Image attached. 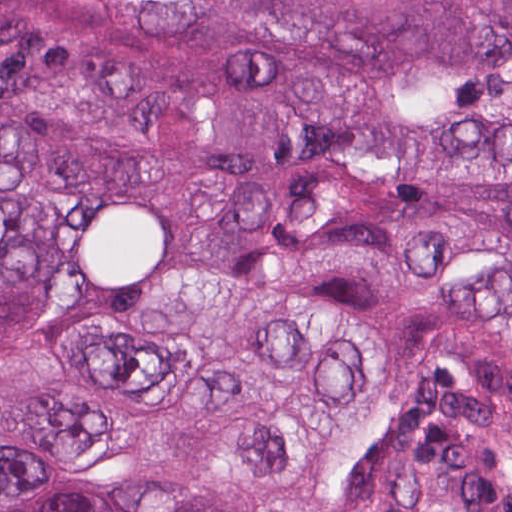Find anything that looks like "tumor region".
Segmentation results:
<instances>
[{
	"label": "tumor region",
	"mask_w": 512,
	"mask_h": 512,
	"mask_svg": "<svg viewBox=\"0 0 512 512\" xmlns=\"http://www.w3.org/2000/svg\"><path fill=\"white\" fill-rule=\"evenodd\" d=\"M0 512H512V0H0Z\"/></svg>",
	"instance_id": "obj_1"
}]
</instances>
